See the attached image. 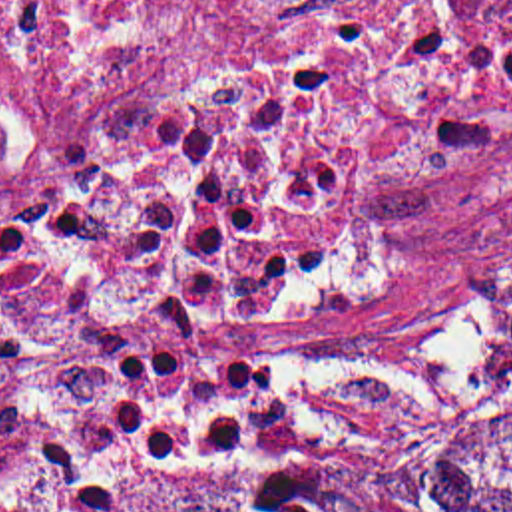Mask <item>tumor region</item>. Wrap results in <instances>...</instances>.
Instances as JSON below:
<instances>
[{"mask_svg": "<svg viewBox=\"0 0 512 512\" xmlns=\"http://www.w3.org/2000/svg\"><path fill=\"white\" fill-rule=\"evenodd\" d=\"M512 364V304L489 330ZM125 512H512V408L382 454H220Z\"/></svg>", "mask_w": 512, "mask_h": 512, "instance_id": "1", "label": "tumor region"}]
</instances>
